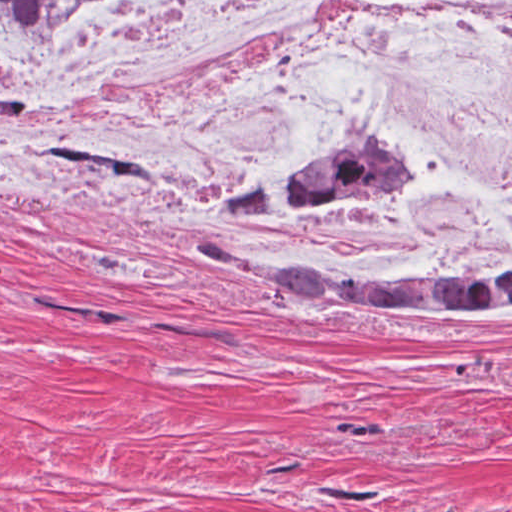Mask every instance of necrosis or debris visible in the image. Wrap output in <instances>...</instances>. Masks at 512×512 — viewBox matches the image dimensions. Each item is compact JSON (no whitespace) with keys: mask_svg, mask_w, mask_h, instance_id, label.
Returning a JSON list of instances; mask_svg holds the SVG:
<instances>
[{"mask_svg":"<svg viewBox=\"0 0 512 512\" xmlns=\"http://www.w3.org/2000/svg\"><path fill=\"white\" fill-rule=\"evenodd\" d=\"M426 185L314 224L365 256L483 265L512 241V0H72L0 29V163L271 216L319 168Z\"/></svg>","mask_w":512,"mask_h":512,"instance_id":"1","label":"necrosis or debris"}]
</instances>
